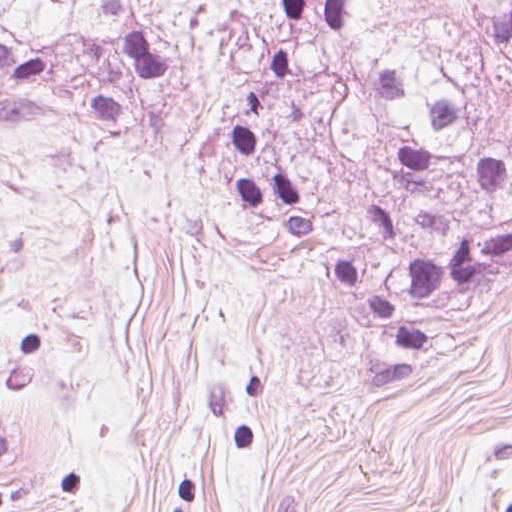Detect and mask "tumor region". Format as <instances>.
<instances>
[{
  "label": "tumor region",
  "instance_id": "1",
  "mask_svg": "<svg viewBox=\"0 0 512 512\" xmlns=\"http://www.w3.org/2000/svg\"><path fill=\"white\" fill-rule=\"evenodd\" d=\"M160 139L386 359L512 290V0H0V134Z\"/></svg>",
  "mask_w": 512,
  "mask_h": 512
}]
</instances>
